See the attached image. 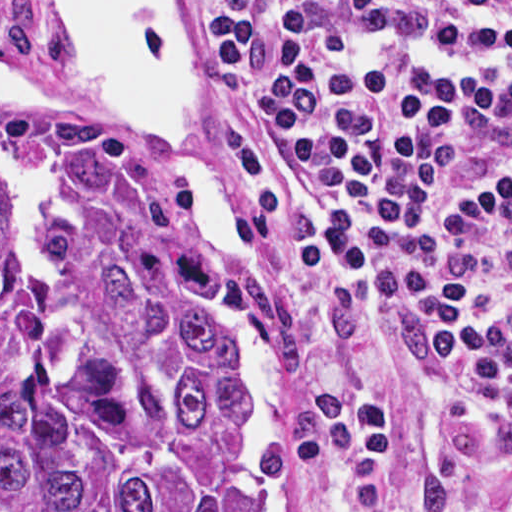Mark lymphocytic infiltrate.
Masks as SVG:
<instances>
[{
  "instance_id": "lymphocytic-infiltrate-1",
  "label": "lymphocytic infiltrate",
  "mask_w": 512,
  "mask_h": 512,
  "mask_svg": "<svg viewBox=\"0 0 512 512\" xmlns=\"http://www.w3.org/2000/svg\"><path fill=\"white\" fill-rule=\"evenodd\" d=\"M289 223L339 290L329 391L393 506L431 377L512 432V0H200Z\"/></svg>"
}]
</instances>
